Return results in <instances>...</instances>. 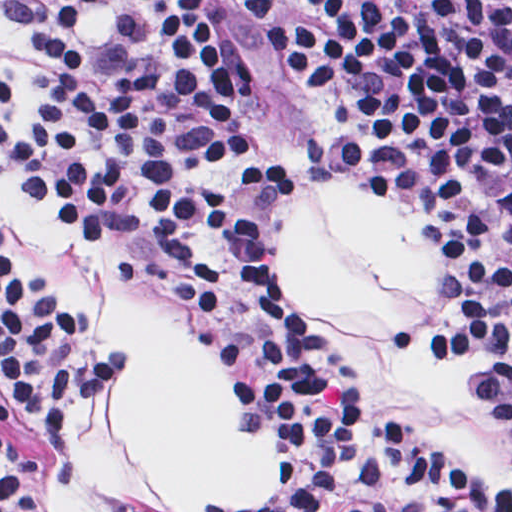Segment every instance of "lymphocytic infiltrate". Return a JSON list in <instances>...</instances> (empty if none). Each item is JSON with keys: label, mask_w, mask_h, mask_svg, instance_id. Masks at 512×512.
I'll return each mask as SVG.
<instances>
[{"label": "lymphocytic infiltrate", "mask_w": 512, "mask_h": 512, "mask_svg": "<svg viewBox=\"0 0 512 512\" xmlns=\"http://www.w3.org/2000/svg\"><path fill=\"white\" fill-rule=\"evenodd\" d=\"M142 1L132 42L33 49L22 63L2 127L16 173L86 259L252 376L259 416L307 455L303 512H507L401 449L355 369L276 286L280 152L241 41L197 0ZM236 3L309 114L311 172L412 176L464 232L477 279L455 311L487 347L512 438V0ZM0 362L63 428L87 424L102 353L1 220ZM14 456L42 470L0 425V512H36Z\"/></svg>", "instance_id": "1"}]
</instances>
